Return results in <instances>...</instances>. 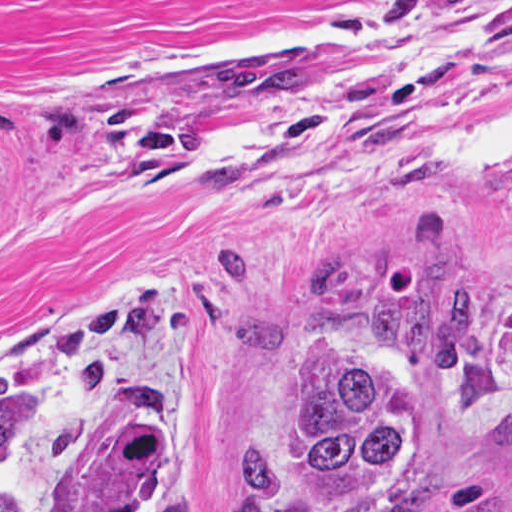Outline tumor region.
<instances>
[{
	"label": "tumor region",
	"mask_w": 512,
	"mask_h": 512,
	"mask_svg": "<svg viewBox=\"0 0 512 512\" xmlns=\"http://www.w3.org/2000/svg\"><path fill=\"white\" fill-rule=\"evenodd\" d=\"M225 90L270 101L307 93V53L221 61ZM486 295L449 260L407 270L352 308L316 345L254 466L243 512H364L409 489L454 443L476 383ZM163 313L153 286L112 311L79 315L59 338L86 386L113 390L117 419L84 512H189L160 493L169 415L134 375L100 358L103 339L143 338ZM56 381L30 369L0 386V512L53 446Z\"/></svg>",
	"instance_id": "e687c5a6"
}]
</instances>
